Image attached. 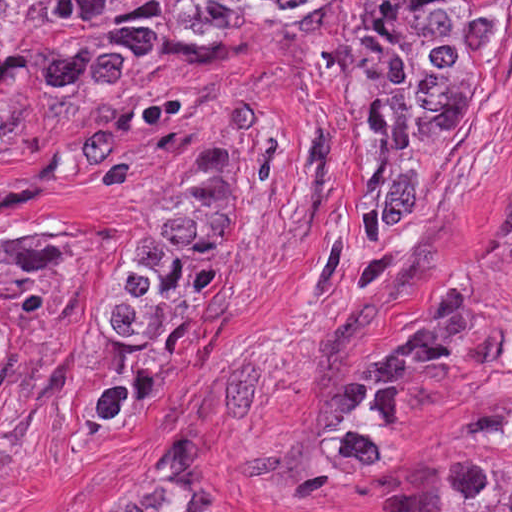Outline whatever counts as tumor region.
Listing matches in <instances>:
<instances>
[{
    "instance_id": "e687c5a6",
    "label": "tumor region",
    "mask_w": 512,
    "mask_h": 512,
    "mask_svg": "<svg viewBox=\"0 0 512 512\" xmlns=\"http://www.w3.org/2000/svg\"><path fill=\"white\" fill-rule=\"evenodd\" d=\"M512 0H191L170 18H105L101 0H0V168L97 140L126 80L330 35L356 48L371 130V209L394 231L443 149L488 104ZM226 206L184 165L117 266L96 345L106 428L151 409L175 346L179 289L217 246ZM3 326L0 324V362ZM144 512H240L210 434L187 487ZM445 512H512V464L457 460Z\"/></svg>"
}]
</instances>
